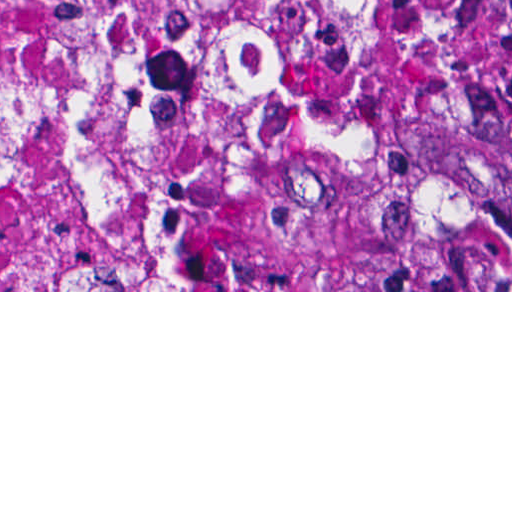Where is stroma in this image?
<instances>
[{
	"label": "stroma",
	"mask_w": 512,
	"mask_h": 512,
	"mask_svg": "<svg viewBox=\"0 0 512 512\" xmlns=\"http://www.w3.org/2000/svg\"><path fill=\"white\" fill-rule=\"evenodd\" d=\"M463 46L473 97V118L478 114L469 68V0H463ZM477 251L508 253L491 231L489 239ZM0 292H512V290H0Z\"/></svg>",
	"instance_id": "1"
}]
</instances>
